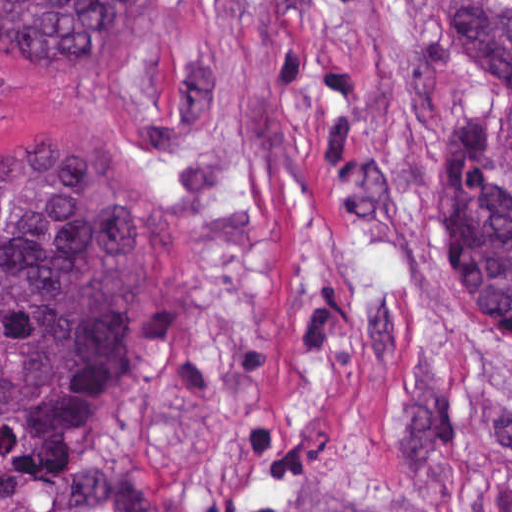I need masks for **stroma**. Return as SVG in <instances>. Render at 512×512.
Returning <instances> with one entry per match:
<instances>
[{
    "label": "stroma",
    "instance_id": "35a3bbf8",
    "mask_svg": "<svg viewBox=\"0 0 512 512\" xmlns=\"http://www.w3.org/2000/svg\"><path fill=\"white\" fill-rule=\"evenodd\" d=\"M494 98L443 0H148L101 64L0 68V157L80 137L175 250L138 377L0 512H512V353L415 237Z\"/></svg>",
    "mask_w": 512,
    "mask_h": 512
}]
</instances>
